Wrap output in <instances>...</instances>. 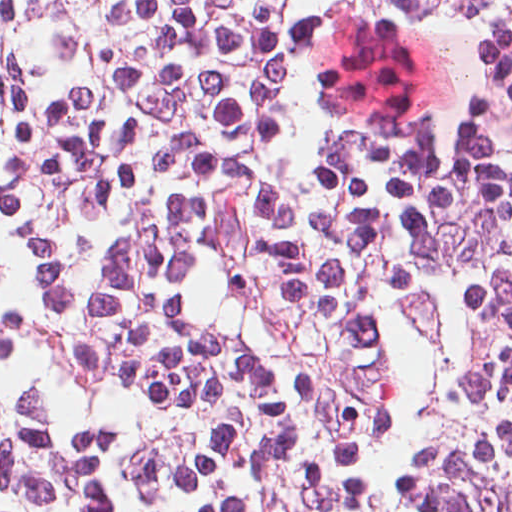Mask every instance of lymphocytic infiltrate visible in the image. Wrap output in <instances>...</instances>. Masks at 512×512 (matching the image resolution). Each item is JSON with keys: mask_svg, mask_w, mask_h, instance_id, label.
<instances>
[{"mask_svg": "<svg viewBox=\"0 0 512 512\" xmlns=\"http://www.w3.org/2000/svg\"><path fill=\"white\" fill-rule=\"evenodd\" d=\"M0 512H512V0H0Z\"/></svg>", "mask_w": 512, "mask_h": 512, "instance_id": "lymphocytic-infiltrate-1", "label": "lymphocytic infiltrate"}]
</instances>
